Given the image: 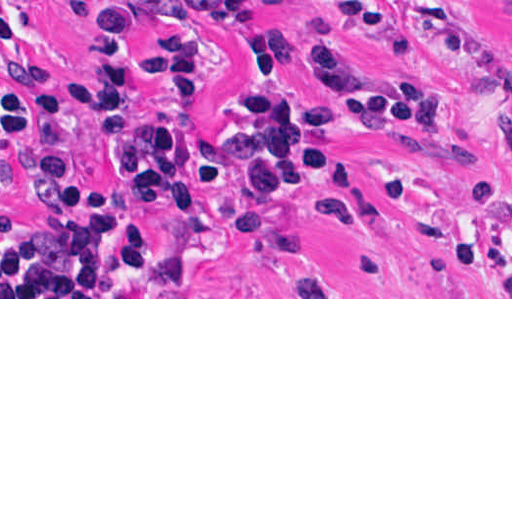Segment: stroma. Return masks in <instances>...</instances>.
I'll use <instances>...</instances> for the list:
<instances>
[{
    "mask_svg": "<svg viewBox=\"0 0 512 512\" xmlns=\"http://www.w3.org/2000/svg\"><path fill=\"white\" fill-rule=\"evenodd\" d=\"M256 18L242 30H222L196 18L132 21L133 53L157 40L194 33L211 57L201 99L183 102L146 81L136 95L156 115L186 119L190 208L158 213L149 196L129 189L103 160L91 107L71 86L88 72L82 35L57 0H37L27 33L0 41V107L12 94L16 62L51 74L64 105L81 175L110 206L135 222H149L154 284H67L0 273V299H512V0H248ZM341 31L359 66L432 84L450 110L448 130L403 124L425 138L469 143L491 157L488 177L475 164L402 138L361 133L316 120L345 106L342 96L293 63L258 70L248 49L270 36L291 35L300 49ZM285 93L299 126L327 148L319 171L283 190L267 210L247 192L232 163L226 175L242 204L283 225L296 243L316 250L274 255L238 238L226 198L200 172L210 140L230 128L246 94ZM336 166L370 186L384 233L347 212L314 216L317 198ZM414 176L446 210L464 196L465 220L448 255L423 226L391 207L386 185ZM34 210L14 179L12 157L0 145V216ZM318 285L324 297H296Z\"/></svg>",
    "mask_w": 512,
    "mask_h": 512,
    "instance_id": "stroma-1",
    "label": "stroma"
}]
</instances>
